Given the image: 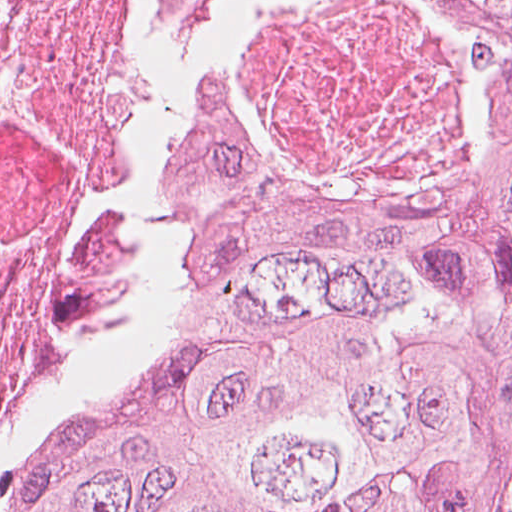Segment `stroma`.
<instances>
[{
  "label": "stroma",
  "instance_id": "obj_1",
  "mask_svg": "<svg viewBox=\"0 0 512 512\" xmlns=\"http://www.w3.org/2000/svg\"><path fill=\"white\" fill-rule=\"evenodd\" d=\"M500 512H512V452L508 462Z\"/></svg>",
  "mask_w": 512,
  "mask_h": 512
}]
</instances>
